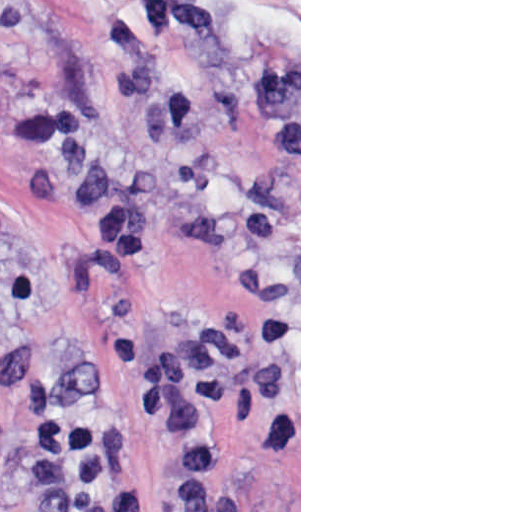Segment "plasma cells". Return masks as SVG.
<instances>
[{
	"mask_svg": "<svg viewBox=\"0 0 512 512\" xmlns=\"http://www.w3.org/2000/svg\"><path fill=\"white\" fill-rule=\"evenodd\" d=\"M243 341L221 328L197 330L172 348L145 354L135 369V397L148 420L161 430L163 442L191 474H213L221 458L209 443L191 435L173 419L172 408L182 397L212 405L235 398Z\"/></svg>",
	"mask_w": 512,
	"mask_h": 512,
	"instance_id": "9512152a",
	"label": "plasma cells"
}]
</instances>
